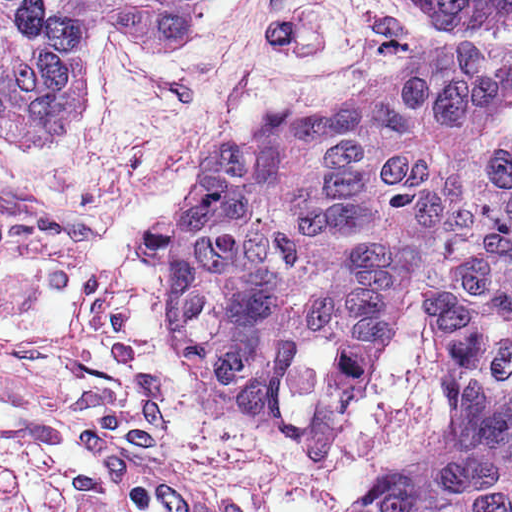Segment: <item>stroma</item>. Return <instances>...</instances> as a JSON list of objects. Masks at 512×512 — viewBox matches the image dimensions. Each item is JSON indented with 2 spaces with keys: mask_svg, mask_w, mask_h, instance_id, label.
I'll return each mask as SVG.
<instances>
[{
  "mask_svg": "<svg viewBox=\"0 0 512 512\" xmlns=\"http://www.w3.org/2000/svg\"><path fill=\"white\" fill-rule=\"evenodd\" d=\"M391 0H202L191 37L128 49L92 35L87 88L53 142L0 150V512H112L75 412H93L222 485L233 512H353L431 447L446 367L422 301L398 311L338 461L269 434L173 332L164 226L223 145L372 92L398 68ZM497 143L512 152V129Z\"/></svg>",
  "mask_w": 512,
  "mask_h": 512,
  "instance_id": "35a3bbf8",
  "label": "stroma"
}]
</instances>
